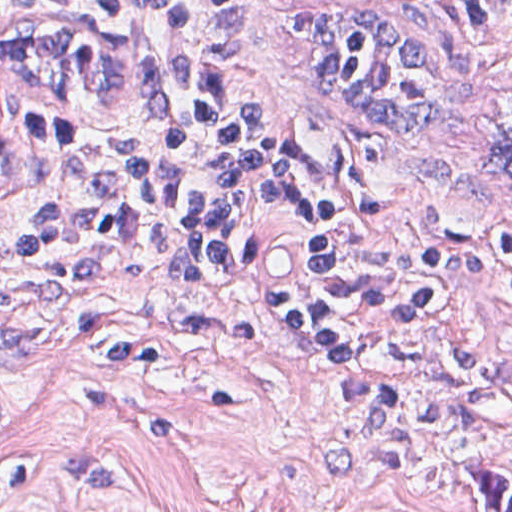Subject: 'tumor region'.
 <instances>
[{"label":"tumor region","mask_w":512,"mask_h":512,"mask_svg":"<svg viewBox=\"0 0 512 512\" xmlns=\"http://www.w3.org/2000/svg\"><path fill=\"white\" fill-rule=\"evenodd\" d=\"M304 98L344 126L417 142L432 137L455 87L447 43L389 16L333 2H294L281 17ZM486 512H512V478L464 466Z\"/></svg>","instance_id":"tumor-region-1"}]
</instances>
